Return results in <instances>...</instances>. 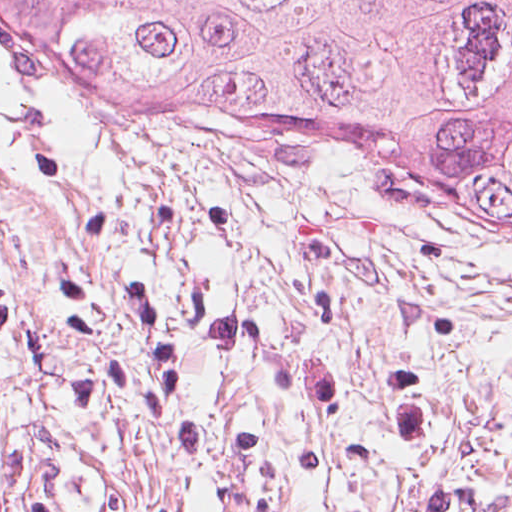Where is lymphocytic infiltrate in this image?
<instances>
[{
    "label": "lymphocytic infiltrate",
    "instance_id": "lymphocytic-infiltrate-1",
    "mask_svg": "<svg viewBox=\"0 0 512 512\" xmlns=\"http://www.w3.org/2000/svg\"><path fill=\"white\" fill-rule=\"evenodd\" d=\"M0 340L25 346L34 360L36 346L20 298L0 287ZM0 512H44V500L29 436L0 434Z\"/></svg>",
    "mask_w": 512,
    "mask_h": 512
}]
</instances>
